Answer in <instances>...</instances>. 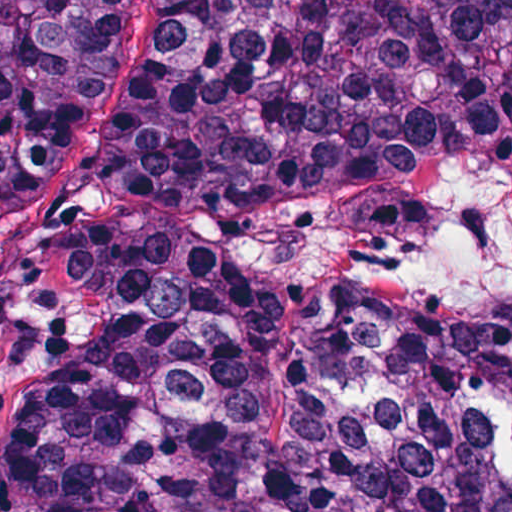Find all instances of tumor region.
<instances>
[{"instance_id":"obj_1","label":"tumor region","mask_w":512,"mask_h":512,"mask_svg":"<svg viewBox=\"0 0 512 512\" xmlns=\"http://www.w3.org/2000/svg\"><path fill=\"white\" fill-rule=\"evenodd\" d=\"M126 0H0L38 198ZM67 416L2 512H512V0H168L57 259Z\"/></svg>"}]
</instances>
